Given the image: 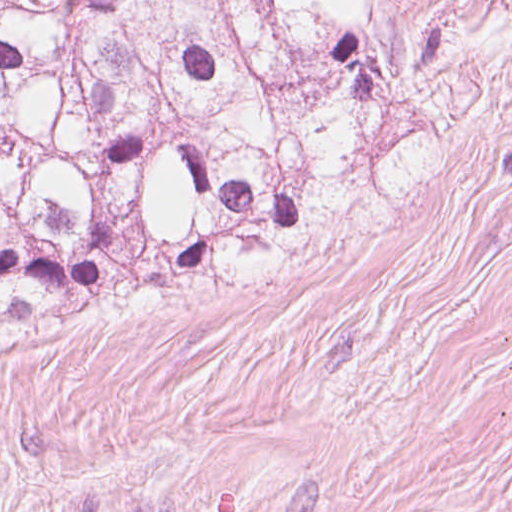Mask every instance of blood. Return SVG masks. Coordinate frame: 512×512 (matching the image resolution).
Returning a JSON list of instances; mask_svg holds the SVG:
<instances>
[{
	"label": "blood",
	"instance_id": "1",
	"mask_svg": "<svg viewBox=\"0 0 512 512\" xmlns=\"http://www.w3.org/2000/svg\"><path fill=\"white\" fill-rule=\"evenodd\" d=\"M216 512H232V494L229 490L221 494Z\"/></svg>",
	"mask_w": 512,
	"mask_h": 512
}]
</instances>
